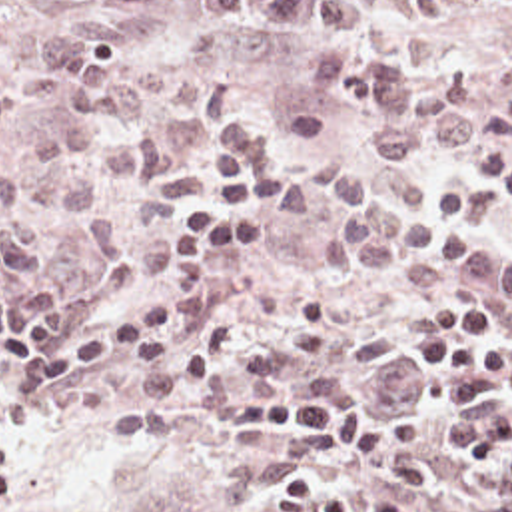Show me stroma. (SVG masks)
I'll list each match as a JSON object with an SVG mask.
<instances>
[{
  "instance_id": "35a3bbf8",
  "label": "stroma",
  "mask_w": 512,
  "mask_h": 512,
  "mask_svg": "<svg viewBox=\"0 0 512 512\" xmlns=\"http://www.w3.org/2000/svg\"><path fill=\"white\" fill-rule=\"evenodd\" d=\"M370 6L362 37L386 59L416 73H460L474 89L468 105L484 137V153L512 143V0H362ZM75 16L123 20L133 49L123 69L143 87L149 55L169 63V97L143 125L153 127L169 155V171L151 185H133L105 169L93 211L109 215L123 239L121 255L99 259L85 225L49 215L47 253L39 269L11 271L5 289H35L57 303L59 329L83 335L121 311L163 299L171 221L201 199L199 141L231 131L249 167L275 177L303 163L348 155L364 173H406L424 197L460 183L490 189L474 171L476 159H456L436 147L430 161L378 155L372 141L380 119L352 95L329 93L317 73L331 47L309 28L263 20H225L201 0H165L149 16H133L91 0H15L0 8V175L23 157L25 145L53 129L61 107L39 105L23 77L39 63L41 39ZM133 129V127H129ZM335 203L307 219H287L267 207L261 243L229 249L217 261L215 317L195 331L135 361L37 395H21L0 431L23 449V485L0 512H271L275 491L301 477L341 485L356 512L390 499L414 512H432L398 481H384L354 453L303 435H251L213 423L233 415L239 401L265 393H227L209 419L149 433H93L135 403L143 375L193 359L235 313L245 321L241 353L267 343L311 291H323L329 313L323 331H384L392 355L376 363L327 365L331 389L356 393L392 409L442 465L448 485L480 511V487L452 479L460 457L438 445L436 421L446 419L444 377H414V349L430 337L422 313L458 293L432 291L376 273H348L323 249ZM484 229L512 243V219L488 217ZM426 293V295H424ZM498 331L512 343L498 303ZM5 353L0 347V373Z\"/></svg>"
}]
</instances>
